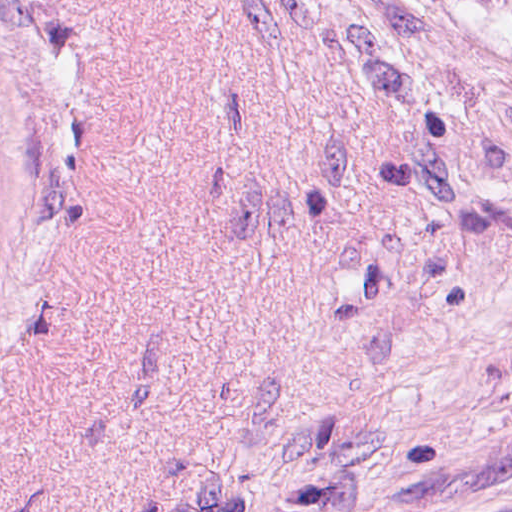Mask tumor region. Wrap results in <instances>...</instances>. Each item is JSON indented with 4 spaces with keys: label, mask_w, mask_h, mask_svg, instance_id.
<instances>
[{
    "label": "tumor region",
    "mask_w": 512,
    "mask_h": 512,
    "mask_svg": "<svg viewBox=\"0 0 512 512\" xmlns=\"http://www.w3.org/2000/svg\"><path fill=\"white\" fill-rule=\"evenodd\" d=\"M471 5L491 13L512 19V0H464Z\"/></svg>",
    "instance_id": "1"
}]
</instances>
